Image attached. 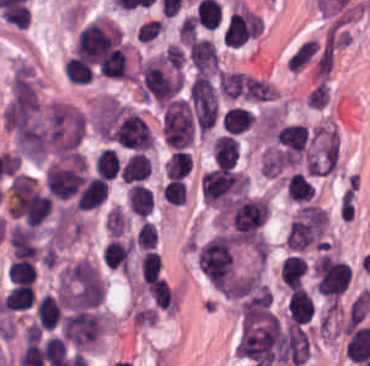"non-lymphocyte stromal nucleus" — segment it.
<instances>
[{"label":"non-lymphocyte stromal nucleus","mask_w":370,"mask_h":366,"mask_svg":"<svg viewBox=\"0 0 370 366\" xmlns=\"http://www.w3.org/2000/svg\"><path fill=\"white\" fill-rule=\"evenodd\" d=\"M59 294L70 308L96 303L105 292V283L94 261L79 258L68 261L57 279Z\"/></svg>","instance_id":"a72fc3eb"},{"label":"non-lymphocyte stromal nucleus","mask_w":370,"mask_h":366,"mask_svg":"<svg viewBox=\"0 0 370 366\" xmlns=\"http://www.w3.org/2000/svg\"><path fill=\"white\" fill-rule=\"evenodd\" d=\"M41 105L38 95L28 77L16 76L10 86L4 124L17 139L38 119Z\"/></svg>","instance_id":"3746e769"},{"label":"non-lymphocyte stromal nucleus","mask_w":370,"mask_h":366,"mask_svg":"<svg viewBox=\"0 0 370 366\" xmlns=\"http://www.w3.org/2000/svg\"><path fill=\"white\" fill-rule=\"evenodd\" d=\"M81 129L82 114L79 108L53 99L15 134L22 152L33 159H42L71 148Z\"/></svg>","instance_id":"dd21d789"}]
</instances>
